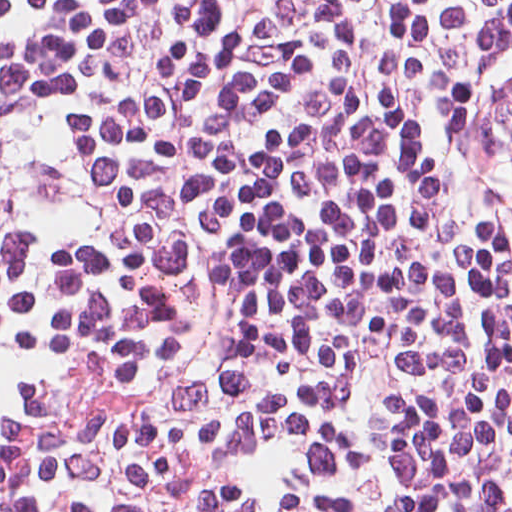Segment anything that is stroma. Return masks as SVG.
Instances as JSON below:
<instances>
[{
  "mask_svg": "<svg viewBox=\"0 0 512 512\" xmlns=\"http://www.w3.org/2000/svg\"><path fill=\"white\" fill-rule=\"evenodd\" d=\"M229 3L263 49L512 256V22L441 0Z\"/></svg>",
  "mask_w": 512,
  "mask_h": 512,
  "instance_id": "1",
  "label": "stroma"
}]
</instances>
